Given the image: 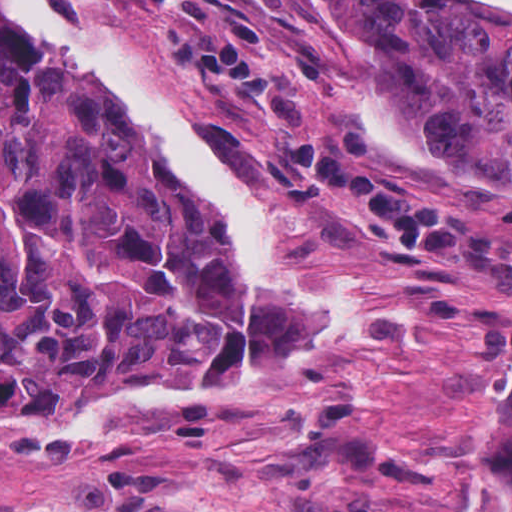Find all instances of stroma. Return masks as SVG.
Listing matches in <instances>:
<instances>
[{
    "label": "stroma",
    "mask_w": 512,
    "mask_h": 512,
    "mask_svg": "<svg viewBox=\"0 0 512 512\" xmlns=\"http://www.w3.org/2000/svg\"><path fill=\"white\" fill-rule=\"evenodd\" d=\"M45 1L77 36L133 39L220 169L276 218L281 274L315 290L361 288L379 333L318 343L287 312L253 301L207 198L120 91L95 68L37 52L0 8L11 48L111 92L237 269L245 316L242 353L216 401L103 407L58 445L0 444V512H457L473 473L472 403L512 374V292L461 257L416 248L368 212L282 175L201 81L178 72L146 16L110 0ZM237 1L279 39L323 40L322 62L294 89L313 125L356 133L396 176L512 241V199L497 188L439 164L428 142L405 133L426 170L396 165L374 143L364 109L392 114L365 43L340 42L311 0Z\"/></svg>",
    "instance_id": "stroma-1"
}]
</instances>
